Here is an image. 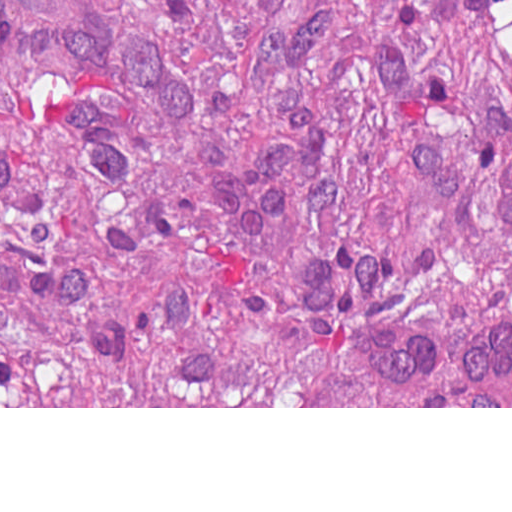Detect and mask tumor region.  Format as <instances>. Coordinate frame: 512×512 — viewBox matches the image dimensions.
Masks as SVG:
<instances>
[{"label":"tumor region","instance_id":"e687c5a6","mask_svg":"<svg viewBox=\"0 0 512 512\" xmlns=\"http://www.w3.org/2000/svg\"><path fill=\"white\" fill-rule=\"evenodd\" d=\"M512 0H1V406H450L353 322L512 311Z\"/></svg>","mask_w":512,"mask_h":512}]
</instances>
